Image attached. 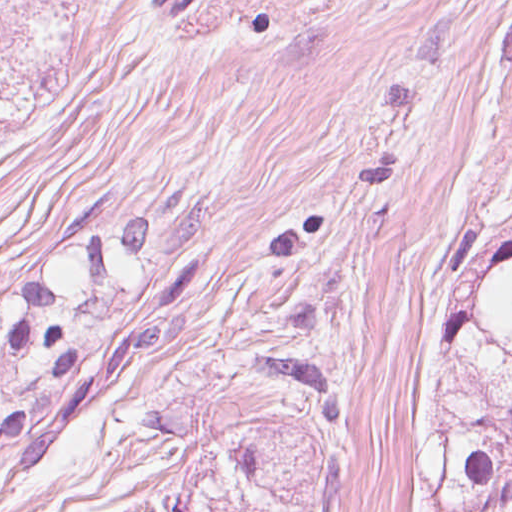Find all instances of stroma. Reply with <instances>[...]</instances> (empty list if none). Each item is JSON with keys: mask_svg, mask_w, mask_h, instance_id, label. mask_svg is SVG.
Returning <instances> with one entry per match:
<instances>
[{"mask_svg": "<svg viewBox=\"0 0 512 512\" xmlns=\"http://www.w3.org/2000/svg\"><path fill=\"white\" fill-rule=\"evenodd\" d=\"M182 181L0 120V273L51 253L83 195L155 217ZM204 187L191 287L0 512H431L404 309L438 262Z\"/></svg>", "mask_w": 512, "mask_h": 512, "instance_id": "stroma-1", "label": "stroma"}]
</instances>
